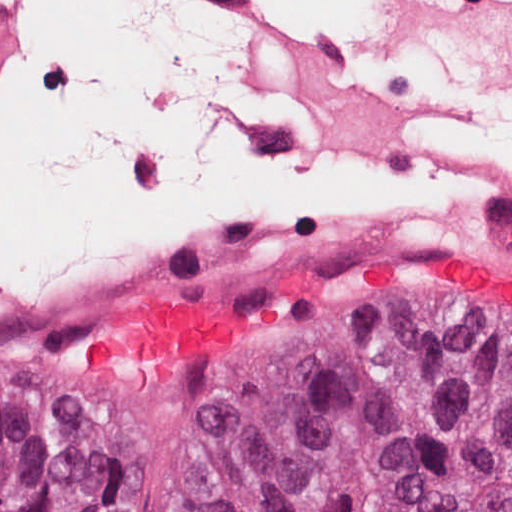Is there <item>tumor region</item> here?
I'll use <instances>...</instances> for the list:
<instances>
[{"label": "tumor region", "mask_w": 512, "mask_h": 512, "mask_svg": "<svg viewBox=\"0 0 512 512\" xmlns=\"http://www.w3.org/2000/svg\"><path fill=\"white\" fill-rule=\"evenodd\" d=\"M375 317L387 322L290 333L200 512H512V344L423 315ZM110 506L111 459L87 416L0 378V512Z\"/></svg>", "instance_id": "obj_1"}]
</instances>
